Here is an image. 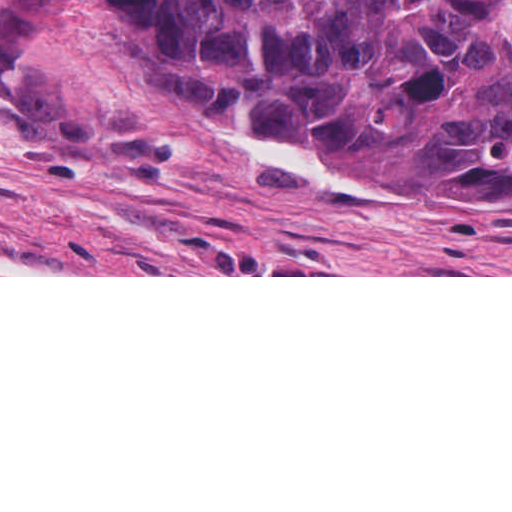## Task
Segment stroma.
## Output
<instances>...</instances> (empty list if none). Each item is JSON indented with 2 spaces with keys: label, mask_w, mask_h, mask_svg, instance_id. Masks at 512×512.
Listing matches in <instances>:
<instances>
[{
  "label": "stroma",
  "mask_w": 512,
  "mask_h": 512,
  "mask_svg": "<svg viewBox=\"0 0 512 512\" xmlns=\"http://www.w3.org/2000/svg\"><path fill=\"white\" fill-rule=\"evenodd\" d=\"M0 277H512V202L442 212L158 107L0 93Z\"/></svg>",
  "instance_id": "stroma-1"
}]
</instances>
